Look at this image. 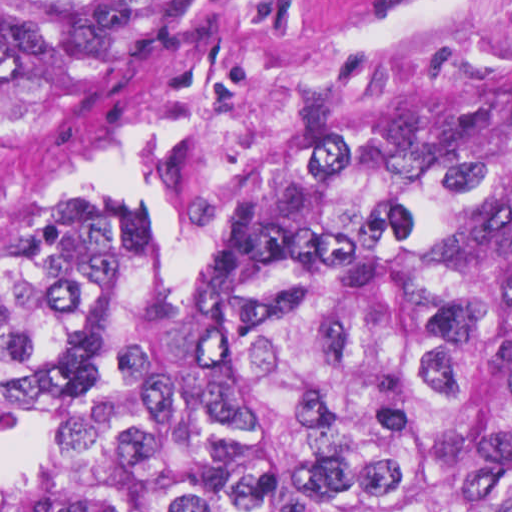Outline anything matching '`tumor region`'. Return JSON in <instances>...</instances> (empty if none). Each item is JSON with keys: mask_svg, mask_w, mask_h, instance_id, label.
I'll use <instances>...</instances> for the list:
<instances>
[{"mask_svg": "<svg viewBox=\"0 0 512 512\" xmlns=\"http://www.w3.org/2000/svg\"><path fill=\"white\" fill-rule=\"evenodd\" d=\"M239 0H0V157ZM80 183L0 238L20 512H512V91L344 77L271 128L239 241Z\"/></svg>", "mask_w": 512, "mask_h": 512, "instance_id": "1", "label": "tumor region"}]
</instances>
